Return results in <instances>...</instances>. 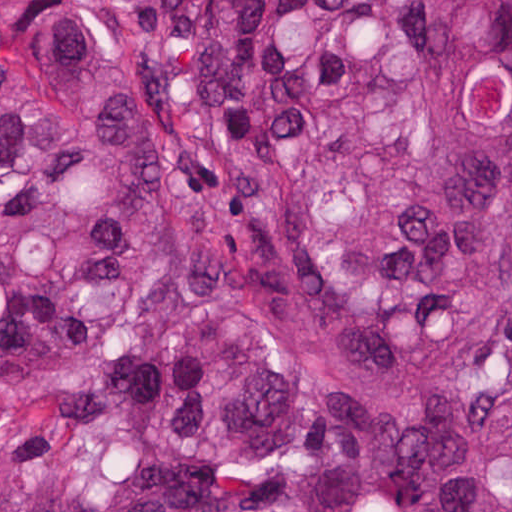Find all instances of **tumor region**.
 <instances>
[{
  "instance_id": "e687c5a6",
  "label": "tumor region",
  "mask_w": 512,
  "mask_h": 512,
  "mask_svg": "<svg viewBox=\"0 0 512 512\" xmlns=\"http://www.w3.org/2000/svg\"><path fill=\"white\" fill-rule=\"evenodd\" d=\"M168 3L0 35V512H512V0Z\"/></svg>"
}]
</instances>
